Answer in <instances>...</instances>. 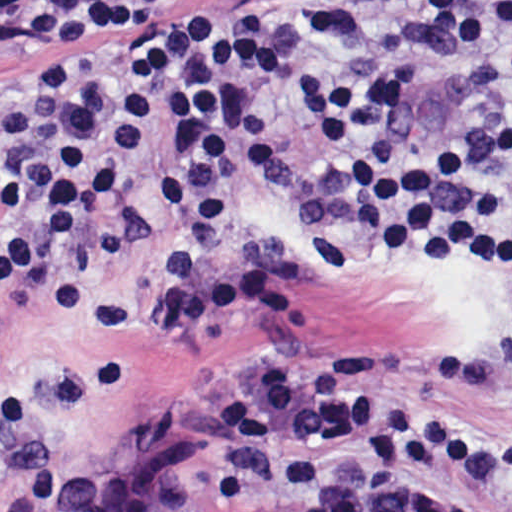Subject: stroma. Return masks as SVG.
<instances>
[{"label": "stroma", "instance_id": "obj_1", "mask_svg": "<svg viewBox=\"0 0 512 512\" xmlns=\"http://www.w3.org/2000/svg\"><path fill=\"white\" fill-rule=\"evenodd\" d=\"M26 1H182L181 15L213 22L236 48L240 35H258L352 69L416 67L424 86L395 119L419 150L512 130V0H0V109L29 76L11 38ZM239 60L295 129L328 128L293 87ZM185 132L183 103L173 100L168 154L134 174L127 203L82 250L86 318L63 322L28 292L0 302V512H235L216 492L221 446L204 412L242 367L278 354L348 358L384 344L473 354L512 330V272L385 253L344 280L323 274L293 187L285 206L268 204L242 161L238 259L285 273L294 310L282 323L226 320L184 341L162 340L148 279L172 225L156 191ZM405 413H444L512 438V393L405 397ZM424 477L478 512H512V487ZM237 512L284 511L263 493Z\"/></svg>", "mask_w": 512, "mask_h": 512}]
</instances>
